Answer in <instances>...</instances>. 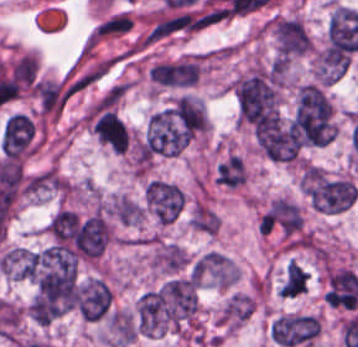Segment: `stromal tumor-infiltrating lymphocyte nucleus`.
<instances>
[{
  "instance_id": "1",
  "label": "stromal tumor-infiltrating lymphocyte nucleus",
  "mask_w": 358,
  "mask_h": 347,
  "mask_svg": "<svg viewBox=\"0 0 358 347\" xmlns=\"http://www.w3.org/2000/svg\"><path fill=\"white\" fill-rule=\"evenodd\" d=\"M0 148L6 157L21 158L35 149V129L29 117L14 112L4 124Z\"/></svg>"
}]
</instances>
